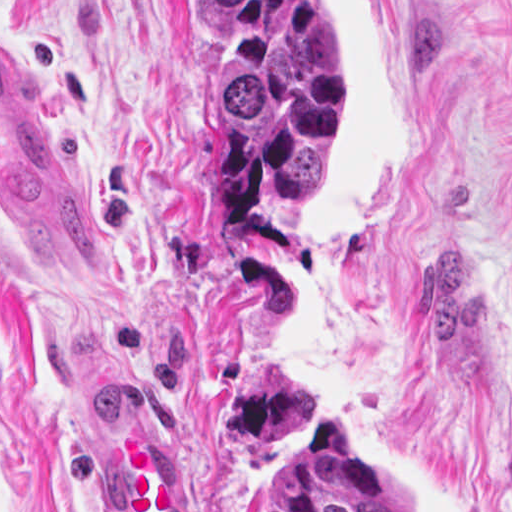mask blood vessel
I'll return each instance as SVG.
<instances>
[{
    "label": "blood vessel",
    "mask_w": 512,
    "mask_h": 512,
    "mask_svg": "<svg viewBox=\"0 0 512 512\" xmlns=\"http://www.w3.org/2000/svg\"><path fill=\"white\" fill-rule=\"evenodd\" d=\"M0 231L50 258H101L99 207L50 122L0 26ZM162 425L123 431L115 454L117 512H193L165 462Z\"/></svg>",
    "instance_id": "8fb6f2fc"
}]
</instances>
